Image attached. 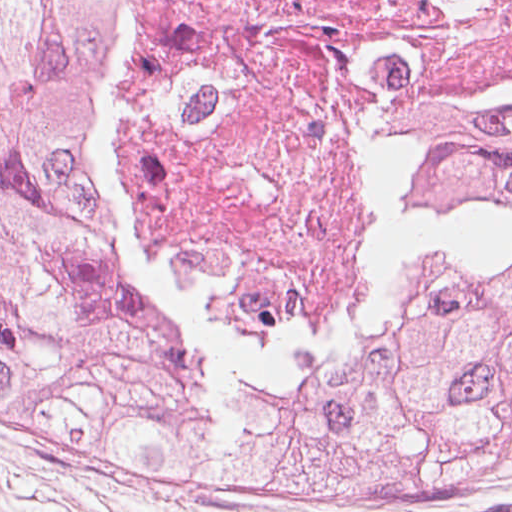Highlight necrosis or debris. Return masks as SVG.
Segmentation results:
<instances>
[{"label": "necrosis or debris", "mask_w": 512, "mask_h": 512, "mask_svg": "<svg viewBox=\"0 0 512 512\" xmlns=\"http://www.w3.org/2000/svg\"><path fill=\"white\" fill-rule=\"evenodd\" d=\"M100 159L204 314L342 342L421 219L414 138L512 114V0H125Z\"/></svg>", "instance_id": "necrosis-or-debris-1"}]
</instances>
